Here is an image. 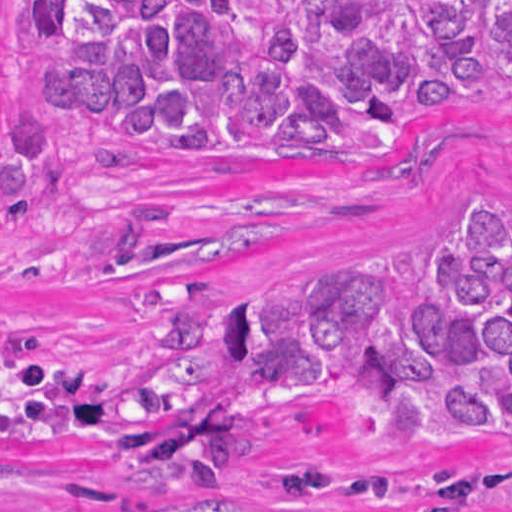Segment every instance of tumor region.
<instances>
[{"label":"tumor region","mask_w":512,"mask_h":512,"mask_svg":"<svg viewBox=\"0 0 512 512\" xmlns=\"http://www.w3.org/2000/svg\"><path fill=\"white\" fill-rule=\"evenodd\" d=\"M39 107L0 92V226L78 171L52 119L169 161L370 164L461 106L512 95V0H14ZM417 279L412 249L330 261L204 305L193 279L146 287L158 347L124 367L60 355L0 320V445L88 441L144 488L253 474L270 413L347 409L369 453L512 441V206L471 203ZM512 475L286 462L298 502L482 512Z\"/></svg>","instance_id":"1"}]
</instances>
